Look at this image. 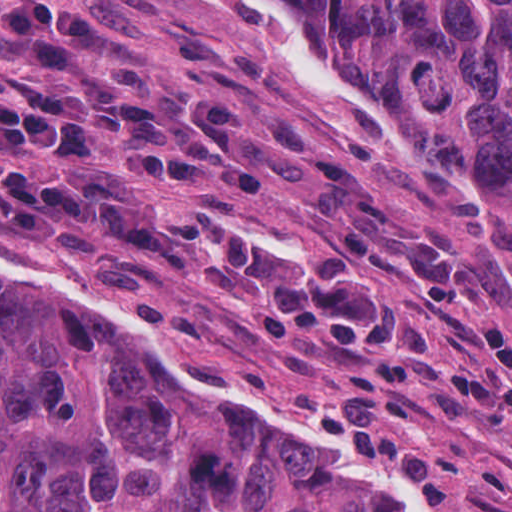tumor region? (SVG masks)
I'll return each instance as SVG.
<instances>
[{
    "label": "tumor region",
    "mask_w": 512,
    "mask_h": 512,
    "mask_svg": "<svg viewBox=\"0 0 512 512\" xmlns=\"http://www.w3.org/2000/svg\"><path fill=\"white\" fill-rule=\"evenodd\" d=\"M296 1L387 124L457 163L512 228V0ZM0 512L401 511L71 298L0 273Z\"/></svg>",
    "instance_id": "e687c5a6"
}]
</instances>
